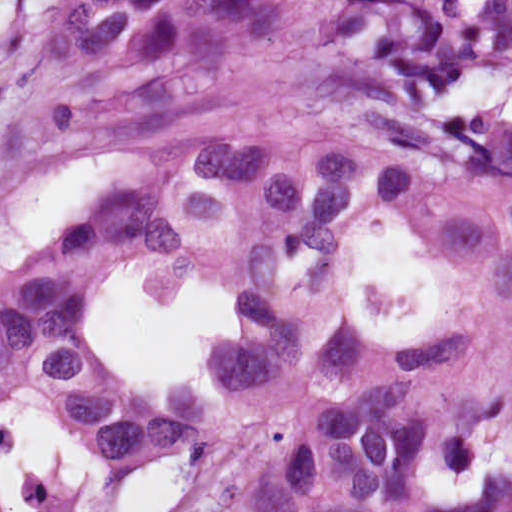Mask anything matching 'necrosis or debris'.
Listing matches in <instances>:
<instances>
[{"mask_svg":"<svg viewBox=\"0 0 512 512\" xmlns=\"http://www.w3.org/2000/svg\"><path fill=\"white\" fill-rule=\"evenodd\" d=\"M424 286L425 277L422 275L409 287L401 290H397L381 278L365 285L371 321L377 322L381 316L386 319L400 318L415 312Z\"/></svg>","mask_w":512,"mask_h":512,"instance_id":"4bbe7bcc","label":"necrosis or debris"}]
</instances>
